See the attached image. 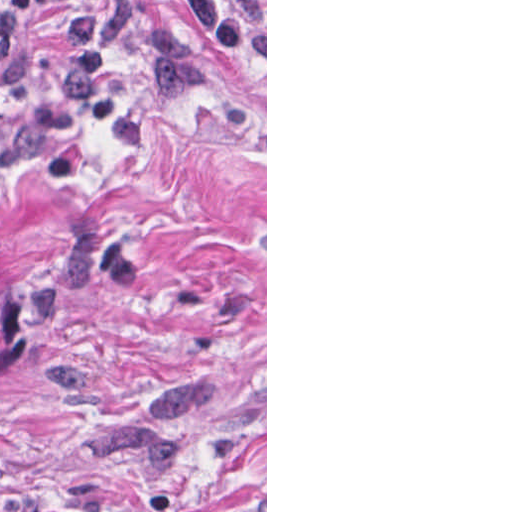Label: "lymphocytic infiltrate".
<instances>
[{"mask_svg":"<svg viewBox=\"0 0 512 512\" xmlns=\"http://www.w3.org/2000/svg\"><path fill=\"white\" fill-rule=\"evenodd\" d=\"M22 17L73 0H4ZM91 6L65 16L64 65L52 101L4 139L16 164L42 155L65 124L88 116L112 141L146 145V122L116 94L113 77L126 54H147L154 79L175 91L204 87L202 60L179 31L150 4L137 0H90ZM197 29L216 47L240 59L266 64V23L256 0H183Z\"/></svg>","mask_w":512,"mask_h":512,"instance_id":"lymphocytic-infiltrate-1","label":"lymphocytic infiltrate"}]
</instances>
